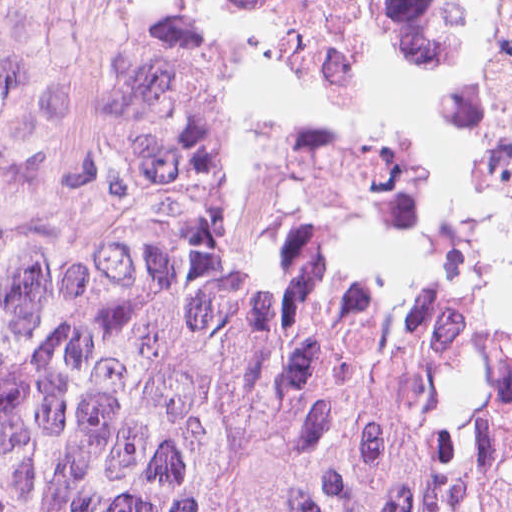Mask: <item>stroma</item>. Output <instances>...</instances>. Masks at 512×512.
Listing matches in <instances>:
<instances>
[{"mask_svg": "<svg viewBox=\"0 0 512 512\" xmlns=\"http://www.w3.org/2000/svg\"><path fill=\"white\" fill-rule=\"evenodd\" d=\"M224 48L237 195L253 232L282 262L325 279L416 286L512 317V55L471 208L383 216L334 179L305 108Z\"/></svg>", "mask_w": 512, "mask_h": 512, "instance_id": "35a3bbf8", "label": "stroma"}]
</instances>
